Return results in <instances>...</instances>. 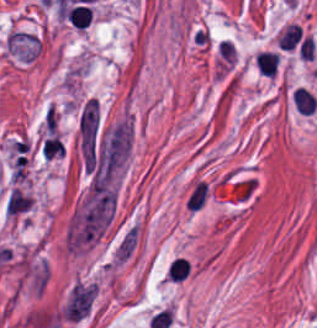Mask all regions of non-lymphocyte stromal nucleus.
Masks as SVG:
<instances>
[{
  "label": "non-lymphocyte stromal nucleus",
  "mask_w": 317,
  "mask_h": 328,
  "mask_svg": "<svg viewBox=\"0 0 317 328\" xmlns=\"http://www.w3.org/2000/svg\"><path fill=\"white\" fill-rule=\"evenodd\" d=\"M139 239V225L131 224L115 243L111 253L113 265L122 266L132 256Z\"/></svg>",
  "instance_id": "1"
}]
</instances>
